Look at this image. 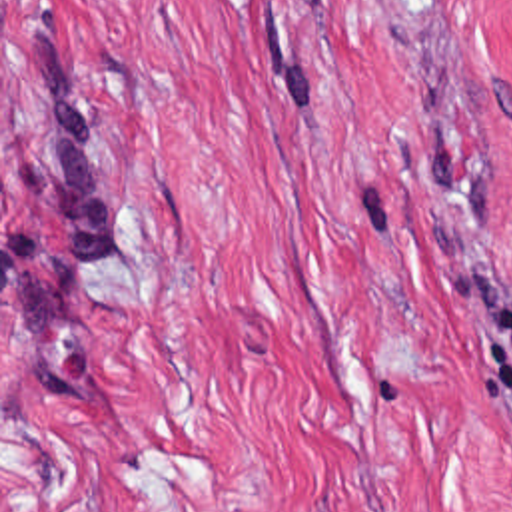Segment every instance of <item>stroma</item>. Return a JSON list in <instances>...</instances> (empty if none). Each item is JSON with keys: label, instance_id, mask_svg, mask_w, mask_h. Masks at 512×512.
I'll use <instances>...</instances> for the list:
<instances>
[{"label": "stroma", "instance_id": "1", "mask_svg": "<svg viewBox=\"0 0 512 512\" xmlns=\"http://www.w3.org/2000/svg\"><path fill=\"white\" fill-rule=\"evenodd\" d=\"M0 512H512V0H0Z\"/></svg>", "mask_w": 512, "mask_h": 512}]
</instances>
